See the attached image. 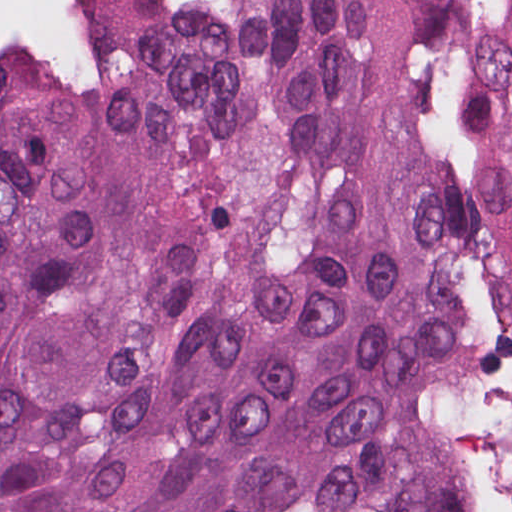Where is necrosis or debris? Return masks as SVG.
Here are the masks:
<instances>
[{
    "instance_id": "obj_1",
    "label": "necrosis or debris",
    "mask_w": 512,
    "mask_h": 512,
    "mask_svg": "<svg viewBox=\"0 0 512 512\" xmlns=\"http://www.w3.org/2000/svg\"><path fill=\"white\" fill-rule=\"evenodd\" d=\"M112 1L0 0V54L21 61L62 94H110L116 72L100 29Z\"/></svg>"
}]
</instances>
